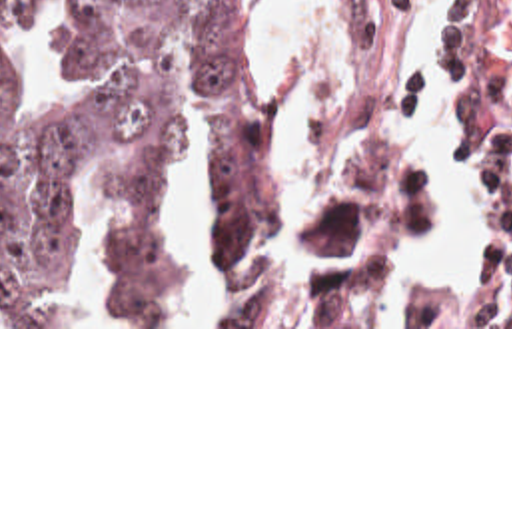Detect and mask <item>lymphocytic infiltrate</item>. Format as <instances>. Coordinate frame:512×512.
Returning <instances> with one entry per match:
<instances>
[{"mask_svg":"<svg viewBox=\"0 0 512 512\" xmlns=\"http://www.w3.org/2000/svg\"><path fill=\"white\" fill-rule=\"evenodd\" d=\"M479 187V265L457 285L439 327H512V123L475 167Z\"/></svg>","mask_w":512,"mask_h":512,"instance_id":"f902f5d3","label":"lymphocytic infiltrate"}]
</instances>
